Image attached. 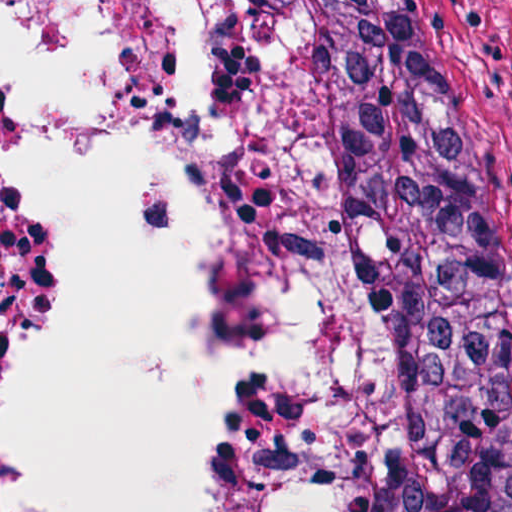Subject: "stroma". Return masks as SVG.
<instances>
[{
  "label": "stroma",
  "mask_w": 512,
  "mask_h": 512,
  "mask_svg": "<svg viewBox=\"0 0 512 512\" xmlns=\"http://www.w3.org/2000/svg\"><path fill=\"white\" fill-rule=\"evenodd\" d=\"M441 7L504 506L512 512V0Z\"/></svg>",
  "instance_id": "35a3bbf8"
}]
</instances>
